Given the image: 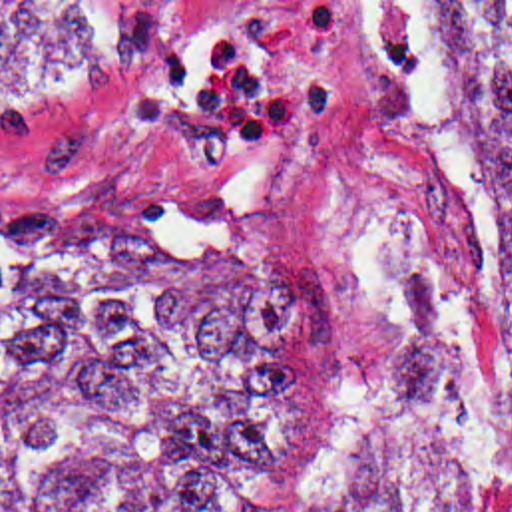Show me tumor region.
<instances>
[{
  "mask_svg": "<svg viewBox=\"0 0 512 512\" xmlns=\"http://www.w3.org/2000/svg\"><path fill=\"white\" fill-rule=\"evenodd\" d=\"M494 213L474 353L412 271L386 370L316 512H512V2H412ZM179 2H0V92L121 68ZM93 219L0 199V512H291L336 448V309L219 197Z\"/></svg>",
  "mask_w": 512,
  "mask_h": 512,
  "instance_id": "tumor-region-1",
  "label": "tumor region"
}]
</instances>
